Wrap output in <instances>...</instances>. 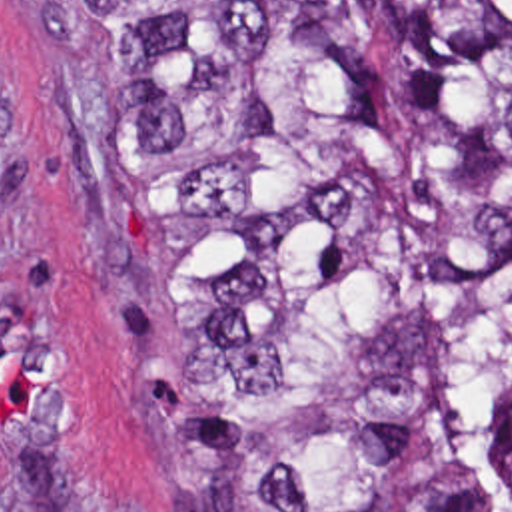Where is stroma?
Wrapping results in <instances>:
<instances>
[{"instance_id": "1", "label": "stroma", "mask_w": 512, "mask_h": 512, "mask_svg": "<svg viewBox=\"0 0 512 512\" xmlns=\"http://www.w3.org/2000/svg\"><path fill=\"white\" fill-rule=\"evenodd\" d=\"M190 343L96 97L39 0H0V512H184L140 381Z\"/></svg>"}]
</instances>
